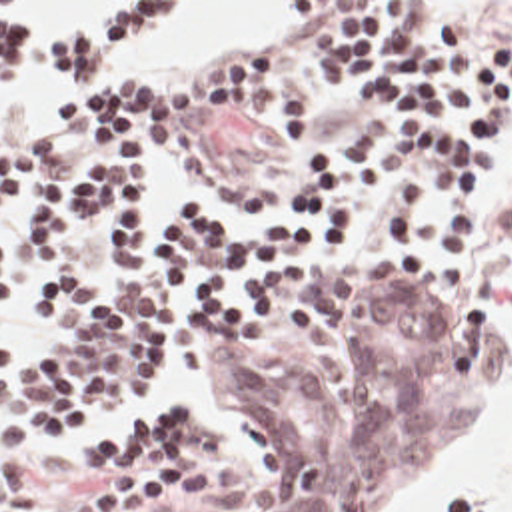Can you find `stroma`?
<instances>
[{
	"mask_svg": "<svg viewBox=\"0 0 512 512\" xmlns=\"http://www.w3.org/2000/svg\"><path fill=\"white\" fill-rule=\"evenodd\" d=\"M0 2H12L36 34H72L114 2H174L134 56L90 86L278 54L286 80L316 92V116L304 126L184 120L168 148L124 160L152 202L186 200L220 220H264L290 208L304 160L354 148L372 118L360 88L312 72L304 2H442L444 20L471 42L512 44V0ZM66 90L54 74L24 70L0 96V132L52 130L64 120ZM28 206H0V242L12 260L0 331L12 351L36 337V282L56 266L26 234ZM80 260L116 298L124 292V270L98 238ZM511 272L512 118L491 126L481 258L469 280L448 270L344 266L290 282L244 339L182 333V375L140 425L14 433L0 423V483L32 479L54 512H400L505 407L512 327L501 284ZM465 503L497 512L493 503Z\"/></svg>",
	"mask_w": 512,
	"mask_h": 512,
	"instance_id": "stroma-1",
	"label": "stroma"
}]
</instances>
